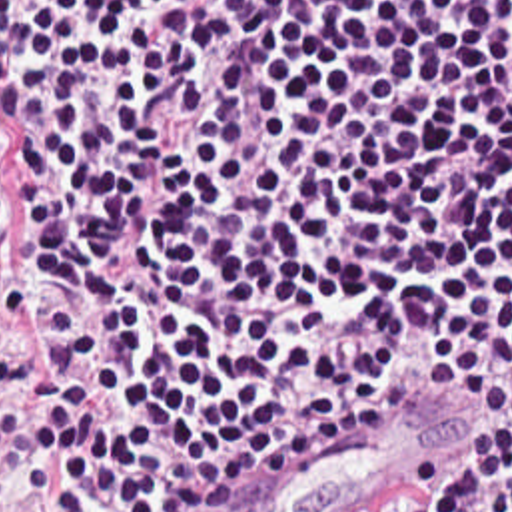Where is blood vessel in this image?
<instances>
[{"label":"blood vessel","instance_id":"1","mask_svg":"<svg viewBox=\"0 0 512 512\" xmlns=\"http://www.w3.org/2000/svg\"><path fill=\"white\" fill-rule=\"evenodd\" d=\"M426 392L440 396L322 408L155 512H336L454 446L468 426V398Z\"/></svg>","mask_w":512,"mask_h":512}]
</instances>
